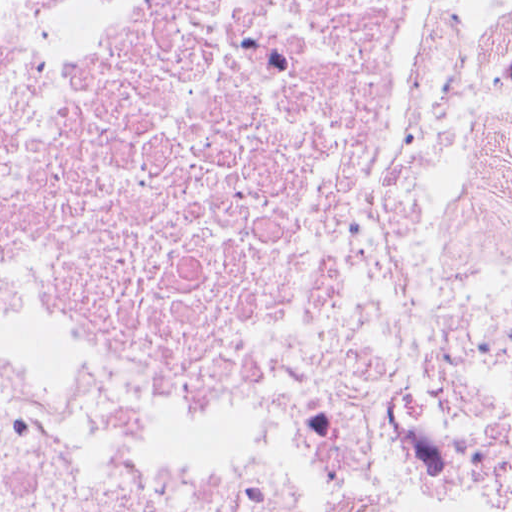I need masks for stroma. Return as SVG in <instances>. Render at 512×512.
Here are the masks:
<instances>
[{"instance_id": "stroma-1", "label": "stroma", "mask_w": 512, "mask_h": 512, "mask_svg": "<svg viewBox=\"0 0 512 512\" xmlns=\"http://www.w3.org/2000/svg\"><path fill=\"white\" fill-rule=\"evenodd\" d=\"M511 0L469 23L411 0L385 160L369 203V308L346 353L320 358H160L87 353L0 323V377L102 370L235 400H372L392 390L399 321L421 257L416 205L435 161L438 116L459 74L503 45ZM512 476V446L412 436L388 472L384 512H444L460 492ZM1 512V511H0Z\"/></svg>"}]
</instances>
